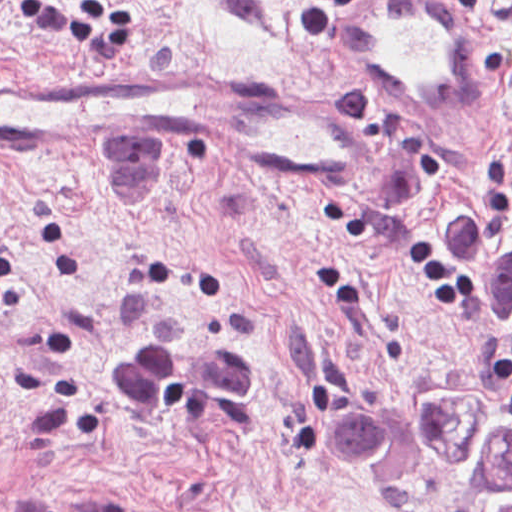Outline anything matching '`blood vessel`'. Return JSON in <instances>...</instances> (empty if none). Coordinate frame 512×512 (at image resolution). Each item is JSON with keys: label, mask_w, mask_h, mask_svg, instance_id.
Listing matches in <instances>:
<instances>
[{"label": "blood vessel", "mask_w": 512, "mask_h": 512, "mask_svg": "<svg viewBox=\"0 0 512 512\" xmlns=\"http://www.w3.org/2000/svg\"><path fill=\"white\" fill-rule=\"evenodd\" d=\"M327 42L347 82L400 120L464 126L492 97L493 49L454 0H354ZM303 91L168 73H0V146L170 155L352 195L377 176L378 154Z\"/></svg>", "instance_id": "obj_1"}]
</instances>
